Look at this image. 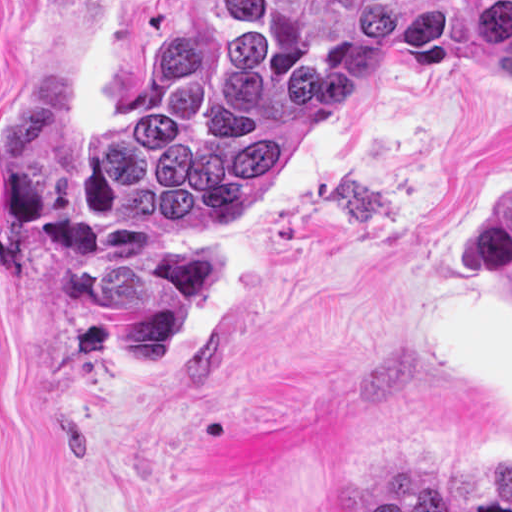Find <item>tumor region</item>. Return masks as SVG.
<instances>
[{
    "label": "tumor region",
    "mask_w": 512,
    "mask_h": 512,
    "mask_svg": "<svg viewBox=\"0 0 512 512\" xmlns=\"http://www.w3.org/2000/svg\"><path fill=\"white\" fill-rule=\"evenodd\" d=\"M358 65L512 76V0H177L122 118H86L65 32L42 37L0 96V241L48 264L38 313L67 367L122 352L137 376L168 371L236 262L210 218L260 188ZM473 256L512 292V187L475 217Z\"/></svg>",
    "instance_id": "1"
}]
</instances>
